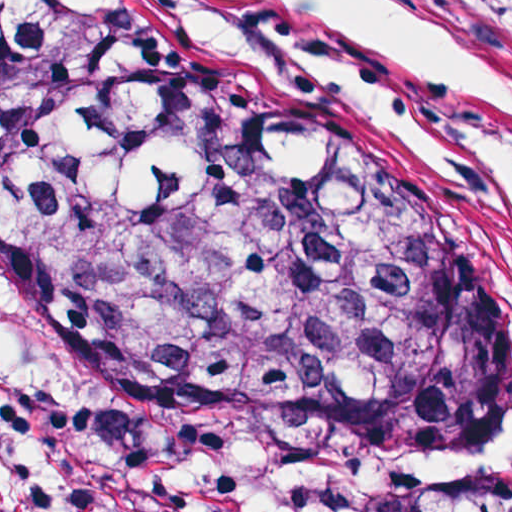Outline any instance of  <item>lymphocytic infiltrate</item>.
Segmentation results:
<instances>
[{
  "instance_id": "lymphocytic-infiltrate-1",
  "label": "lymphocytic infiltrate",
  "mask_w": 512,
  "mask_h": 512,
  "mask_svg": "<svg viewBox=\"0 0 512 512\" xmlns=\"http://www.w3.org/2000/svg\"><path fill=\"white\" fill-rule=\"evenodd\" d=\"M0 512H100L64 405L0 337Z\"/></svg>"
}]
</instances>
